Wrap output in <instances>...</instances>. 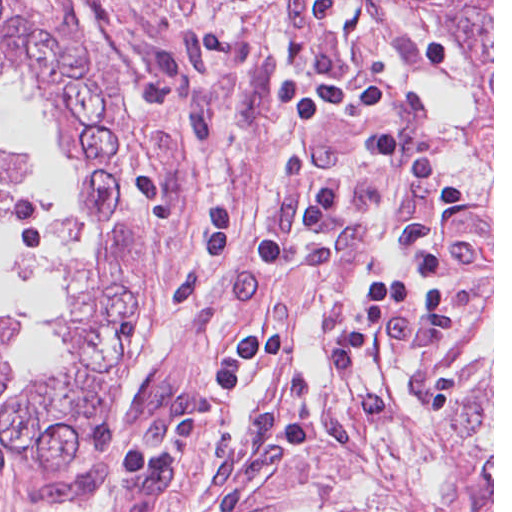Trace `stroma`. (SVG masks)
I'll return each instance as SVG.
<instances>
[{
	"label": "stroma",
	"mask_w": 512,
	"mask_h": 512,
	"mask_svg": "<svg viewBox=\"0 0 512 512\" xmlns=\"http://www.w3.org/2000/svg\"><path fill=\"white\" fill-rule=\"evenodd\" d=\"M0 512H36L19 462L0 453Z\"/></svg>",
	"instance_id": "35a3bbf8"
}]
</instances>
